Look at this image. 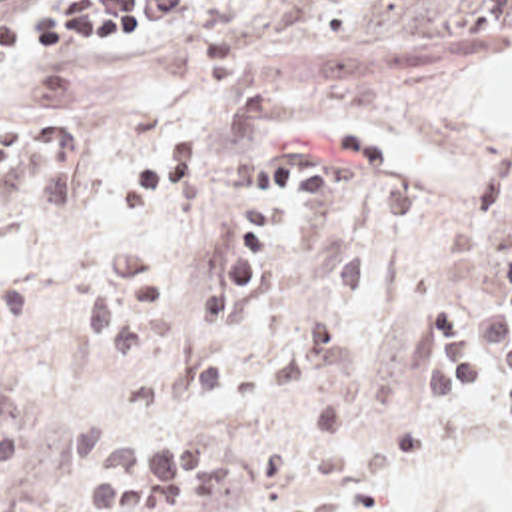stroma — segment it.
Masks as SVG:
<instances>
[{"instance_id": "obj_1", "label": "stroma", "mask_w": 512, "mask_h": 512, "mask_svg": "<svg viewBox=\"0 0 512 512\" xmlns=\"http://www.w3.org/2000/svg\"><path fill=\"white\" fill-rule=\"evenodd\" d=\"M29 0L9 15H35ZM512 43V0H216L143 19L91 51H23L0 69V127L47 111L85 123V159L123 173L192 123L208 159L169 211L165 279L210 277L248 219L262 163L288 143L366 131L412 183V219L298 217L240 317L147 353H105L73 303L79 275L143 215L95 197L59 217L0 209V512H91L87 480L119 450L200 448L238 488L192 512H512V407L412 389L438 311L472 345L512 251V123H438L440 93Z\"/></svg>"}]
</instances>
